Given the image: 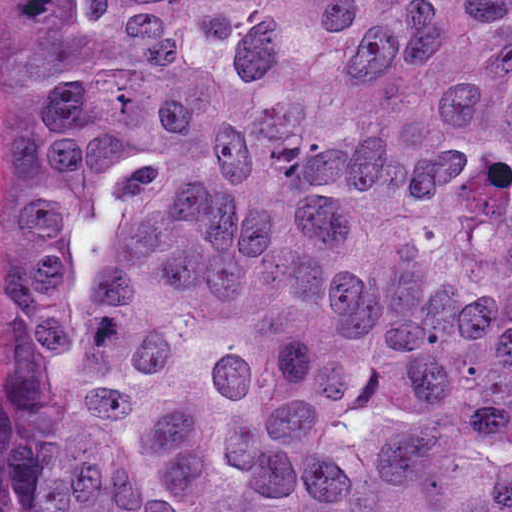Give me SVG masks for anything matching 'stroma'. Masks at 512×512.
I'll list each match as a JSON object with an SVG mask.
<instances>
[{
	"label": "stroma",
	"mask_w": 512,
	"mask_h": 512,
	"mask_svg": "<svg viewBox=\"0 0 512 512\" xmlns=\"http://www.w3.org/2000/svg\"><path fill=\"white\" fill-rule=\"evenodd\" d=\"M21 163V0H0V257Z\"/></svg>",
	"instance_id": "obj_1"
}]
</instances>
